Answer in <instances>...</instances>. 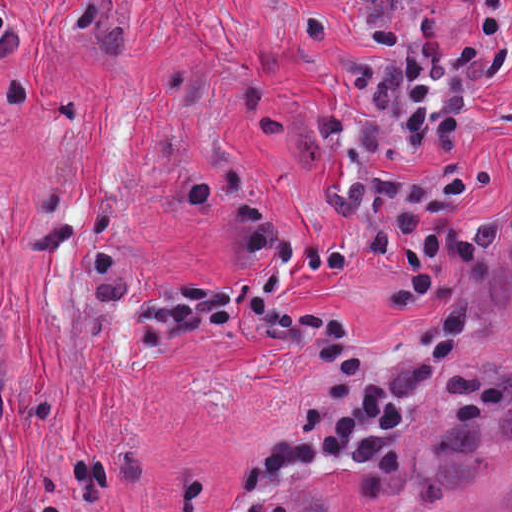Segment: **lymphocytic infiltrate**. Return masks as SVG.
I'll use <instances>...</instances> for the list:
<instances>
[{"label": "lymphocytic infiltrate", "mask_w": 512, "mask_h": 512, "mask_svg": "<svg viewBox=\"0 0 512 512\" xmlns=\"http://www.w3.org/2000/svg\"><path fill=\"white\" fill-rule=\"evenodd\" d=\"M370 33L331 82V170L339 187L316 243L275 251L249 283L207 291L191 283L110 302L129 363L152 358L177 331H230L293 347L327 371L308 409L288 420L245 470L255 491L315 461H384L420 436L438 398L458 302L432 320L425 344L388 373L374 371L350 327L279 294L295 262L315 274L393 258L405 279L393 306L424 300L444 276L478 260L470 195L478 178L463 136L512 87V0H351ZM22 22L0 0V50Z\"/></svg>", "instance_id": "lymphocytic-infiltrate-1"}]
</instances>
